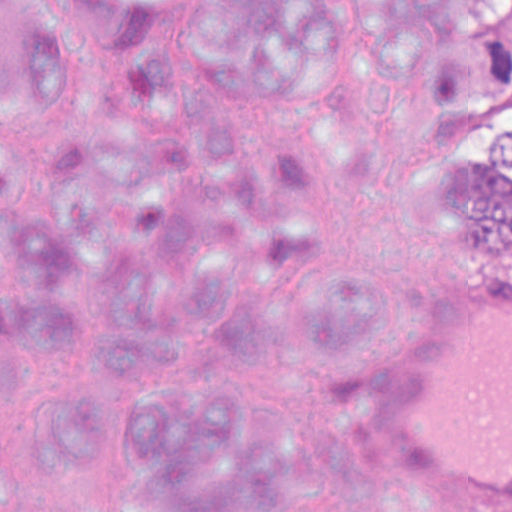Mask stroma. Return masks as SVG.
Masks as SVG:
<instances>
[{"mask_svg":"<svg viewBox=\"0 0 512 512\" xmlns=\"http://www.w3.org/2000/svg\"><path fill=\"white\" fill-rule=\"evenodd\" d=\"M406 84L412 91L414 97L419 102L427 118L433 123L434 114L426 97L422 73H401ZM464 237L460 240L466 260L469 266V272L483 268H512V256L510 257H489L471 241L465 224L461 221Z\"/></svg>","mask_w":512,"mask_h":512,"instance_id":"1","label":"stroma"}]
</instances>
